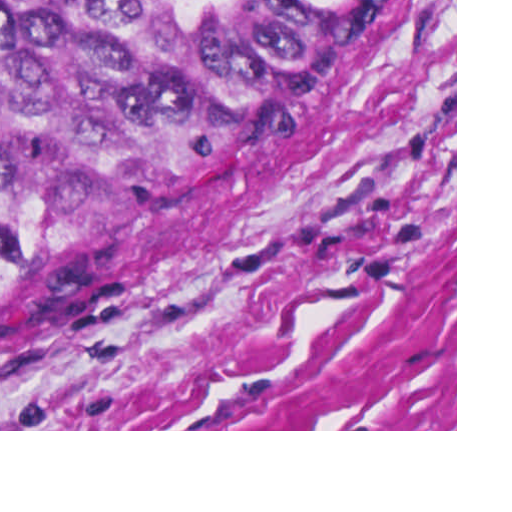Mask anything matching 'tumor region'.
Wrapping results in <instances>:
<instances>
[{"instance_id": "obj_1", "label": "tumor region", "mask_w": 512, "mask_h": 512, "mask_svg": "<svg viewBox=\"0 0 512 512\" xmlns=\"http://www.w3.org/2000/svg\"><path fill=\"white\" fill-rule=\"evenodd\" d=\"M377 0H0V381L312 90Z\"/></svg>"}]
</instances>
